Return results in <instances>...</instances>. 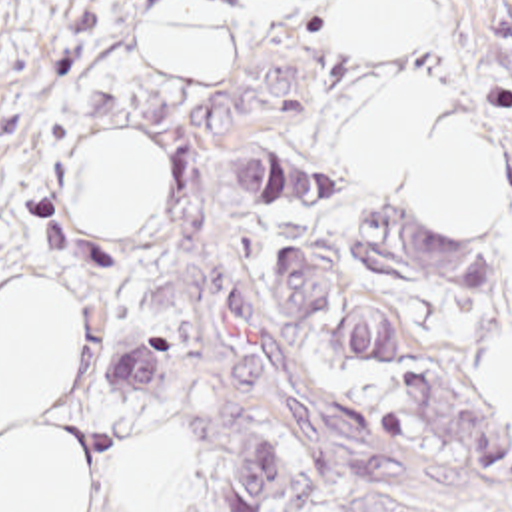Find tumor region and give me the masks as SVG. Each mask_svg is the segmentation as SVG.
<instances>
[{
  "mask_svg": "<svg viewBox=\"0 0 512 512\" xmlns=\"http://www.w3.org/2000/svg\"><path fill=\"white\" fill-rule=\"evenodd\" d=\"M19 0H0V42ZM233 202L330 200V182L318 176L285 144H243L227 162ZM360 270L386 284L410 290L446 288L460 294L492 290L488 246L454 236L438 224L404 222L388 212L360 216L352 242ZM342 276V260L332 266L312 244L283 246L269 260L265 288L289 320H312L326 306ZM380 308H350L328 322L326 352L342 370H386L400 358V340ZM121 390L159 398V334L125 350L113 370ZM213 485L235 512H263L291 485L269 443H255L245 465ZM318 512H444L406 497L350 489Z\"/></svg>",
  "mask_w": 512,
  "mask_h": 512,
  "instance_id": "e687c5a6",
  "label": "tumor region"
}]
</instances>
